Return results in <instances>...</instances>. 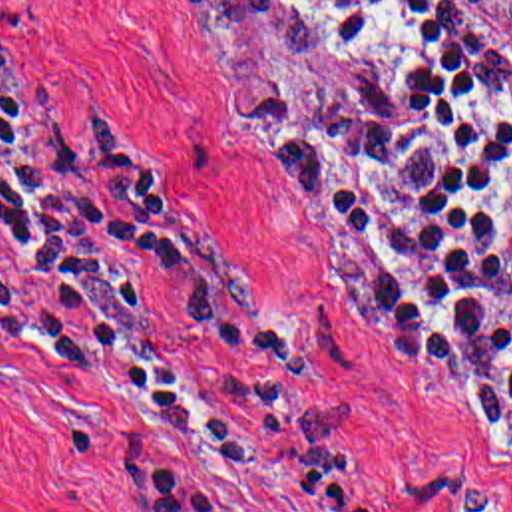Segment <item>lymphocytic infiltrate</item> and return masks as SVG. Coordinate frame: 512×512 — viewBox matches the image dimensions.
Here are the masks:
<instances>
[{"instance_id": "obj_1", "label": "lymphocytic infiltrate", "mask_w": 512, "mask_h": 512, "mask_svg": "<svg viewBox=\"0 0 512 512\" xmlns=\"http://www.w3.org/2000/svg\"><path fill=\"white\" fill-rule=\"evenodd\" d=\"M175 1L292 37L340 71L338 103H218L216 137L306 206L386 344L461 372L511 424V59L441 0ZM117 254L175 288L254 420H228L191 382ZM0 342L41 352L214 463H274L282 441L296 495L316 507L396 512L346 491L342 433L292 326L101 121L61 101L41 133L0 95ZM125 512L218 511L193 475L129 459Z\"/></svg>"}]
</instances>
